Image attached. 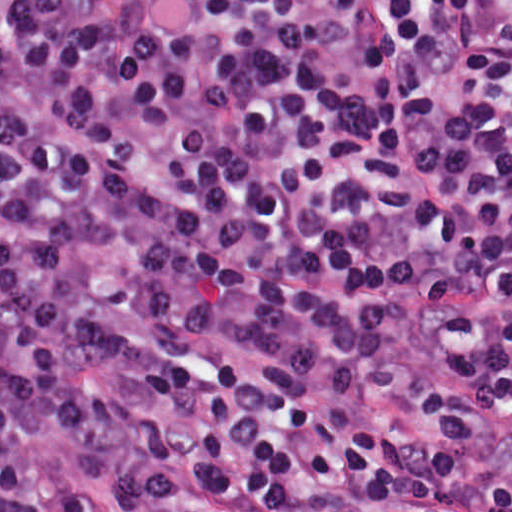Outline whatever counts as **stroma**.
Segmentation results:
<instances>
[{
  "mask_svg": "<svg viewBox=\"0 0 512 512\" xmlns=\"http://www.w3.org/2000/svg\"><path fill=\"white\" fill-rule=\"evenodd\" d=\"M445 318L442 305L416 312L401 328L400 338L373 379H351L329 389L357 401L370 417L448 451L482 476L512 483V428L489 442L466 441L452 436L441 419L415 405V361ZM32 444L42 468L61 481L87 512H132L106 492L91 467L73 457L48 431L36 433ZM171 486L178 489L176 497L151 512H299L275 509L246 494L209 489L181 472L171 474ZM305 512H512V507L421 510L399 503H345Z\"/></svg>",
  "mask_w": 512,
  "mask_h": 512,
  "instance_id": "1",
  "label": "stroma"
}]
</instances>
